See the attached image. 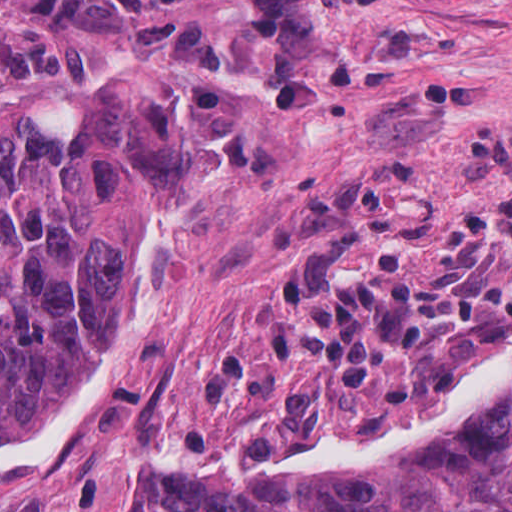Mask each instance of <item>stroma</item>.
<instances>
[{
  "mask_svg": "<svg viewBox=\"0 0 512 512\" xmlns=\"http://www.w3.org/2000/svg\"><path fill=\"white\" fill-rule=\"evenodd\" d=\"M130 67L203 74L241 158L71 396L0 436V512H113L199 470L364 478L415 439L355 467L226 449L320 434L512 330V0H0V114L73 131Z\"/></svg>",
  "mask_w": 512,
  "mask_h": 512,
  "instance_id": "obj_1",
  "label": "stroma"
}]
</instances>
